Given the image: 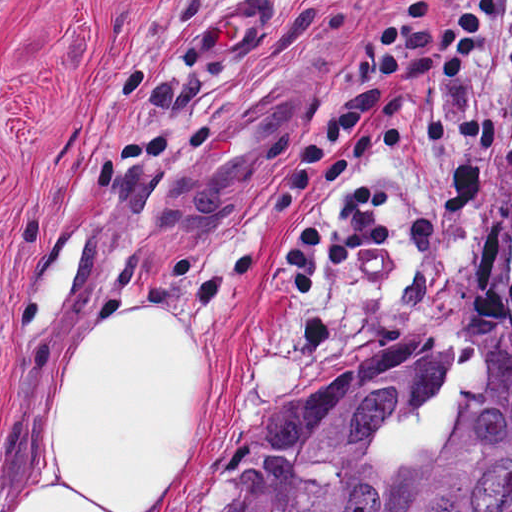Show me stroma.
Listing matches in <instances>:
<instances>
[{"instance_id": "1", "label": "stroma", "mask_w": 512, "mask_h": 512, "mask_svg": "<svg viewBox=\"0 0 512 512\" xmlns=\"http://www.w3.org/2000/svg\"><path fill=\"white\" fill-rule=\"evenodd\" d=\"M413 0H0V512H29L60 437L71 365L134 310L218 357L224 414L178 512H227L263 418L380 343L437 334L451 359L392 419V464L442 450L464 400L512 362V164L467 136L378 158L393 238L291 298L275 260L348 196L360 171L275 223L296 159L334 125L373 31ZM264 5L267 32L198 86H175L185 35L232 5ZM454 0H421L435 16ZM311 105L242 208L183 229V168L264 89ZM512 126V79L483 87Z\"/></svg>"}]
</instances>
